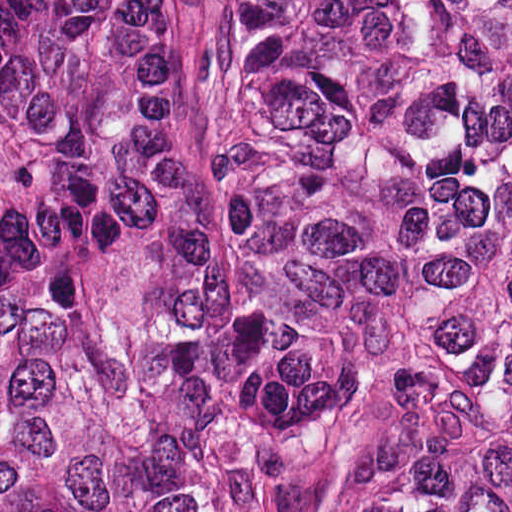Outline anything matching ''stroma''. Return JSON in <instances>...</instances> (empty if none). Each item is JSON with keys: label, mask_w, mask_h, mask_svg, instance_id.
<instances>
[{"label": "stroma", "mask_w": 512, "mask_h": 512, "mask_svg": "<svg viewBox=\"0 0 512 512\" xmlns=\"http://www.w3.org/2000/svg\"><path fill=\"white\" fill-rule=\"evenodd\" d=\"M213 1L170 0L178 40L199 82L228 202V132L213 49ZM259 415L277 512H298L303 472L333 419L368 412H440L491 421L472 408L417 390H309L273 398L252 355Z\"/></svg>", "instance_id": "35a3bbf8"}]
</instances>
